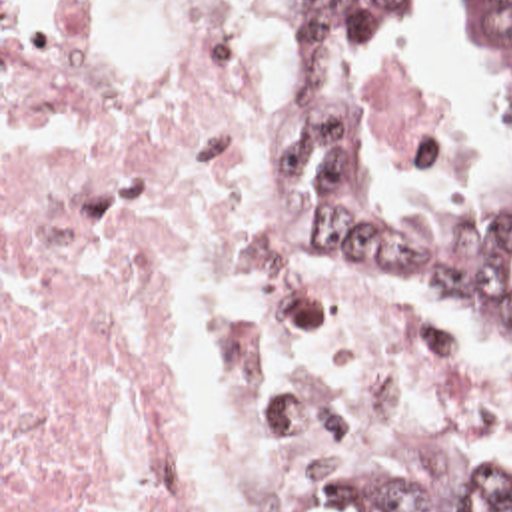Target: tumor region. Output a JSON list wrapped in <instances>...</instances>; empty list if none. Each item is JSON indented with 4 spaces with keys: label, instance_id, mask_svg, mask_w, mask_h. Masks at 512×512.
I'll return each mask as SVG.
<instances>
[{
    "label": "tumor region",
    "instance_id": "e687c5a6",
    "mask_svg": "<svg viewBox=\"0 0 512 512\" xmlns=\"http://www.w3.org/2000/svg\"><path fill=\"white\" fill-rule=\"evenodd\" d=\"M403 0H294L300 62L373 66L391 52ZM449 40L485 70L507 146V212L475 236H425L385 202L341 100L321 96L288 124L272 178L315 256L361 266L399 290L437 298L473 322L481 342L512 364V0H455ZM361 512H512V473H465L417 456H345Z\"/></svg>",
    "mask_w": 512,
    "mask_h": 512
}]
</instances>
